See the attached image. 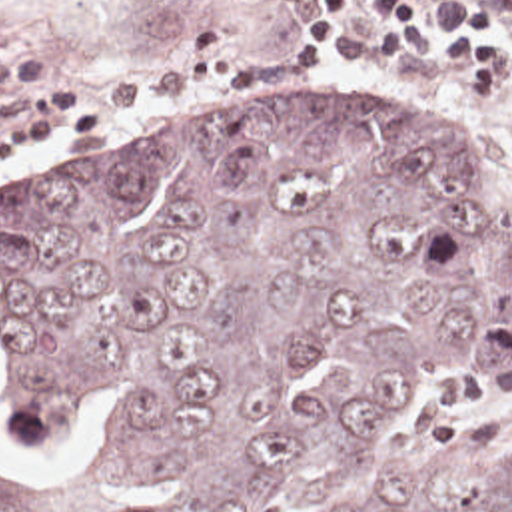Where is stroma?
Segmentation results:
<instances>
[{
    "instance_id": "stroma-1",
    "label": "stroma",
    "mask_w": 512,
    "mask_h": 512,
    "mask_svg": "<svg viewBox=\"0 0 512 512\" xmlns=\"http://www.w3.org/2000/svg\"><path fill=\"white\" fill-rule=\"evenodd\" d=\"M368 1L356 0V21L366 29ZM289 21L271 0H0V47H29L37 55L35 79L0 83V89L75 87L99 101L109 83L163 71L201 25L233 27L241 53L273 55ZM105 109H111L105 133L37 137L19 160H0V206L79 168L185 141L253 133L323 113L428 109L474 148L490 188L512 214V91H472L454 69L412 53L384 61L368 53L337 55L325 73H303L301 61V81L281 89H205ZM444 434H512V368L492 376H464L448 364L410 368L386 424L360 460L356 484L366 496L386 490Z\"/></svg>"
}]
</instances>
